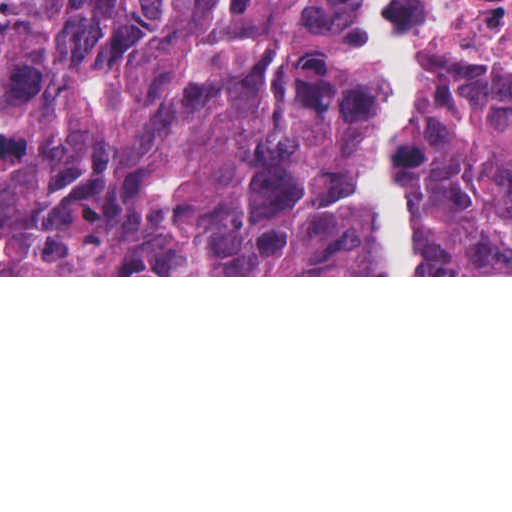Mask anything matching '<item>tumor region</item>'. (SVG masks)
I'll return each mask as SVG.
<instances>
[{"label":"tumor region","mask_w":512,"mask_h":512,"mask_svg":"<svg viewBox=\"0 0 512 512\" xmlns=\"http://www.w3.org/2000/svg\"><path fill=\"white\" fill-rule=\"evenodd\" d=\"M349 0H0V275H348ZM420 275H512V67L422 98Z\"/></svg>","instance_id":"tumor-region-1"}]
</instances>
